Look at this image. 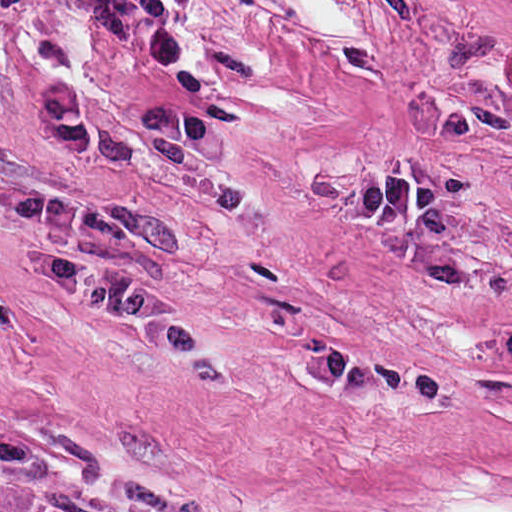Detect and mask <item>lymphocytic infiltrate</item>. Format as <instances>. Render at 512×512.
<instances>
[{"instance_id": "obj_1", "label": "lymphocytic infiltrate", "mask_w": 512, "mask_h": 512, "mask_svg": "<svg viewBox=\"0 0 512 512\" xmlns=\"http://www.w3.org/2000/svg\"><path fill=\"white\" fill-rule=\"evenodd\" d=\"M184 0H0V54L90 157L146 192L224 186L217 144L164 67Z\"/></svg>"}]
</instances>
